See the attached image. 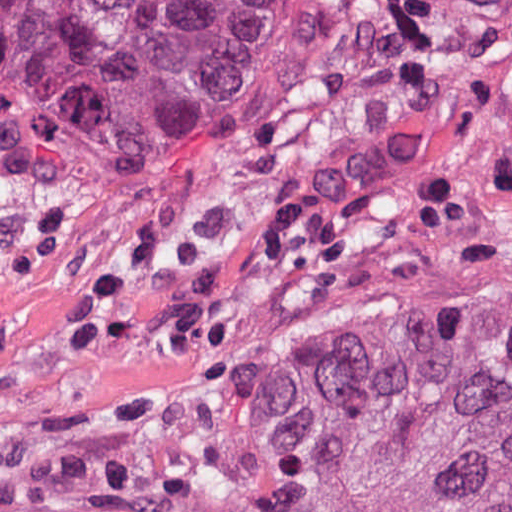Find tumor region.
<instances>
[{
	"instance_id": "tumor-region-1",
	"label": "tumor region",
	"mask_w": 512,
	"mask_h": 512,
	"mask_svg": "<svg viewBox=\"0 0 512 512\" xmlns=\"http://www.w3.org/2000/svg\"><path fill=\"white\" fill-rule=\"evenodd\" d=\"M461 45L512 49V0H0V267ZM0 512H512V309L284 328L114 443L0 446Z\"/></svg>"
}]
</instances>
